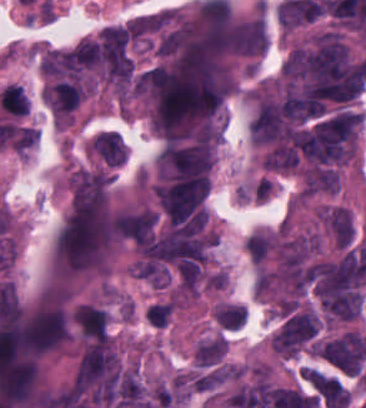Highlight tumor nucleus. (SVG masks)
<instances>
[{
	"mask_svg": "<svg viewBox=\"0 0 366 408\" xmlns=\"http://www.w3.org/2000/svg\"><path fill=\"white\" fill-rule=\"evenodd\" d=\"M318 318L308 305L289 313L270 338L274 351L292 355L306 343L317 330Z\"/></svg>",
	"mask_w": 366,
	"mask_h": 408,
	"instance_id": "obj_1",
	"label": "tumor nucleus"
},
{
	"mask_svg": "<svg viewBox=\"0 0 366 408\" xmlns=\"http://www.w3.org/2000/svg\"><path fill=\"white\" fill-rule=\"evenodd\" d=\"M38 132L35 128L20 126L15 128L11 147L16 152H23L36 139Z\"/></svg>",
	"mask_w": 366,
	"mask_h": 408,
	"instance_id": "obj_2",
	"label": "tumor nucleus"
}]
</instances>
